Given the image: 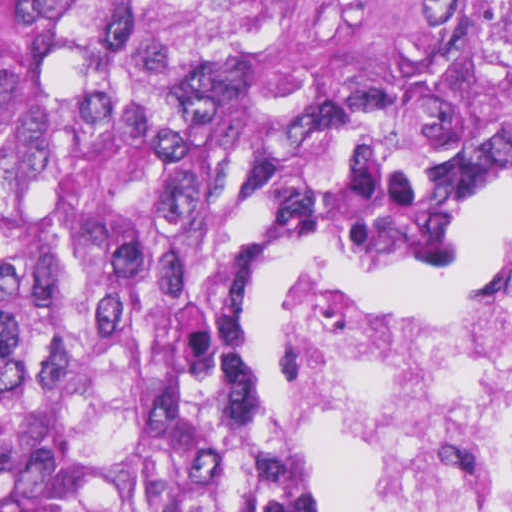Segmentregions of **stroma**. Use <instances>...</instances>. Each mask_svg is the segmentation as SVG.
I'll use <instances>...</instances> for the list:
<instances>
[{
    "label": "stroma",
    "instance_id": "stroma-1",
    "mask_svg": "<svg viewBox=\"0 0 512 512\" xmlns=\"http://www.w3.org/2000/svg\"><path fill=\"white\" fill-rule=\"evenodd\" d=\"M488 190H512V136L506 127L501 147L476 196ZM504 240L485 250L477 281L468 290L442 303H457L475 297L496 247ZM449 250L450 240L426 245H336L315 240L295 245L284 265L265 279L237 325V348L259 391L272 427L276 403L273 293L279 275L301 269L354 281L326 263L348 259L407 263L430 259ZM285 452L305 483V512H342L370 483L390 475V457L337 427L323 441L305 450Z\"/></svg>",
    "mask_w": 512,
    "mask_h": 512
}]
</instances>
